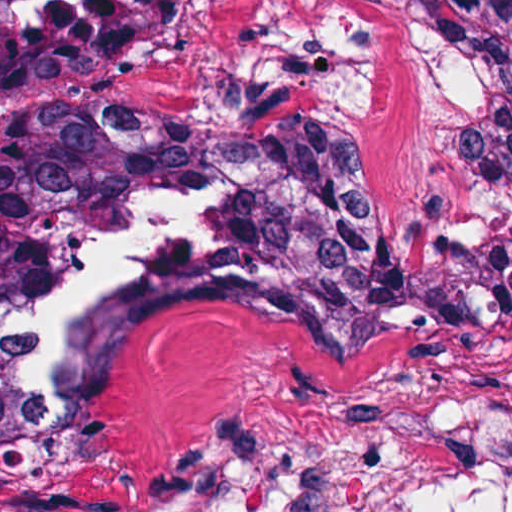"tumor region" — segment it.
<instances>
[{
  "label": "tumor region",
  "instance_id": "tumor-region-1",
  "mask_svg": "<svg viewBox=\"0 0 512 512\" xmlns=\"http://www.w3.org/2000/svg\"><path fill=\"white\" fill-rule=\"evenodd\" d=\"M411 1L447 36L460 58L467 89L463 159L489 208V245L442 243L421 270L463 288L483 350L512 373V0ZM182 10L183 0H152L128 55L169 29ZM115 110L130 124L156 136H243L336 152L328 135L312 130L218 135L190 120L147 116L117 104ZM353 266H391L365 206L357 222L314 249L239 271H183L165 279L127 306L115 355L152 319L184 302L229 299L292 276ZM30 283L0 259V326ZM22 418L30 466L53 485L60 474L101 449L94 411L67 423H37L23 413Z\"/></svg>",
  "mask_w": 512,
  "mask_h": 512
}]
</instances>
